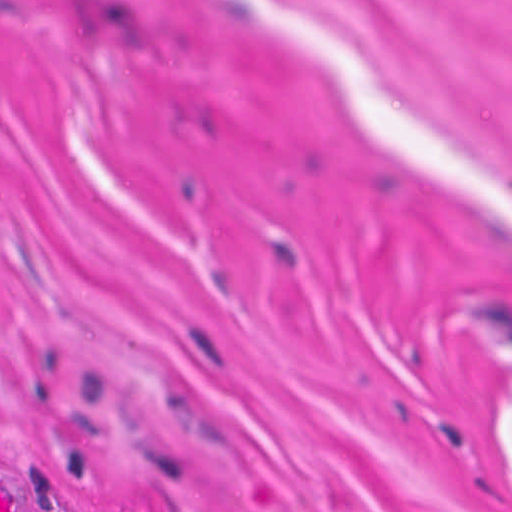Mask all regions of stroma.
I'll use <instances>...</instances> for the list:
<instances>
[{"label": "stroma", "mask_w": 512, "mask_h": 512, "mask_svg": "<svg viewBox=\"0 0 512 512\" xmlns=\"http://www.w3.org/2000/svg\"><path fill=\"white\" fill-rule=\"evenodd\" d=\"M0 512H512V0H0Z\"/></svg>", "instance_id": "35a3bbf8"}]
</instances>
